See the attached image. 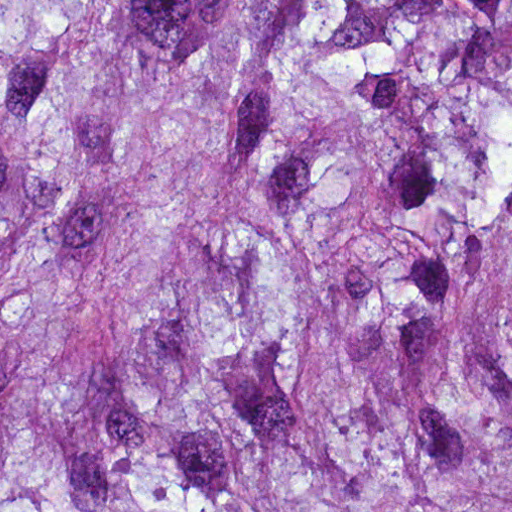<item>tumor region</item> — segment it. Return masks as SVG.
<instances>
[{
  "label": "tumor region",
  "instance_id": "e687c5a6",
  "mask_svg": "<svg viewBox=\"0 0 512 512\" xmlns=\"http://www.w3.org/2000/svg\"><path fill=\"white\" fill-rule=\"evenodd\" d=\"M0 512H512V0H0Z\"/></svg>",
  "mask_w": 512,
  "mask_h": 512
}]
</instances>
